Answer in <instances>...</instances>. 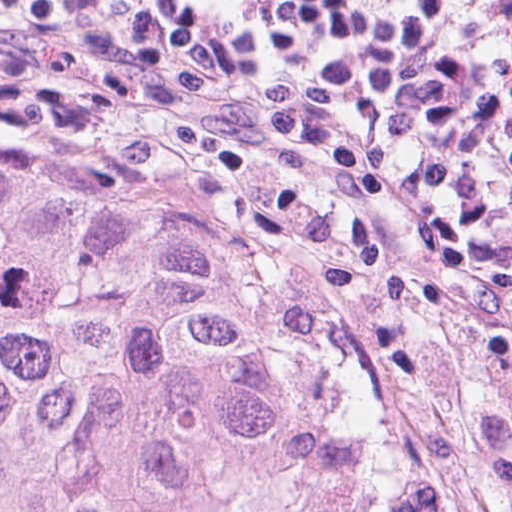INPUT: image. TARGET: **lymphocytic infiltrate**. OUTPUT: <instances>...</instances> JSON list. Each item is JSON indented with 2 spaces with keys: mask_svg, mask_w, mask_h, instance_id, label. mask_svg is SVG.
Wrapping results in <instances>:
<instances>
[{
  "mask_svg": "<svg viewBox=\"0 0 512 512\" xmlns=\"http://www.w3.org/2000/svg\"><path fill=\"white\" fill-rule=\"evenodd\" d=\"M0 50L29 59H60L88 74L109 82L126 85H170L177 86L166 78L145 69L112 63L92 57L58 55L35 51L0 41ZM366 218V217H365ZM367 219V218H366ZM369 220V219H367ZM370 221V220H369ZM372 222V221H370ZM382 230L376 223L372 222ZM383 231V230H382ZM487 288L497 297L512 317V279L506 281H471Z\"/></svg>",
  "mask_w": 512,
  "mask_h": 512,
  "instance_id": "f902f5d3",
  "label": "lymphocytic infiltrate"
}]
</instances>
